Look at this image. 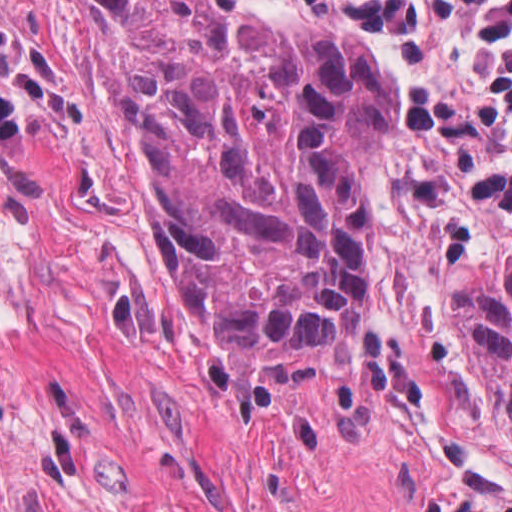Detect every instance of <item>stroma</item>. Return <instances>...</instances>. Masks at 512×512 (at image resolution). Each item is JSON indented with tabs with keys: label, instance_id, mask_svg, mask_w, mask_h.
<instances>
[{
	"label": "stroma",
	"instance_id": "1",
	"mask_svg": "<svg viewBox=\"0 0 512 512\" xmlns=\"http://www.w3.org/2000/svg\"><path fill=\"white\" fill-rule=\"evenodd\" d=\"M264 13L308 25L342 29L386 62V126L369 161V232L448 370L512 479V444L497 426V405L458 346V293L470 275L490 263L512 260V213L480 208L477 238L458 262H443L436 247L434 214L398 185L402 175L425 173L457 180L495 145L487 132L469 144L422 133L406 117L409 96L421 91L477 109L489 95L491 50L462 4L460 12L433 20L423 65L397 62L384 39L340 17L350 0H246Z\"/></svg>",
	"mask_w": 512,
	"mask_h": 512
}]
</instances>
